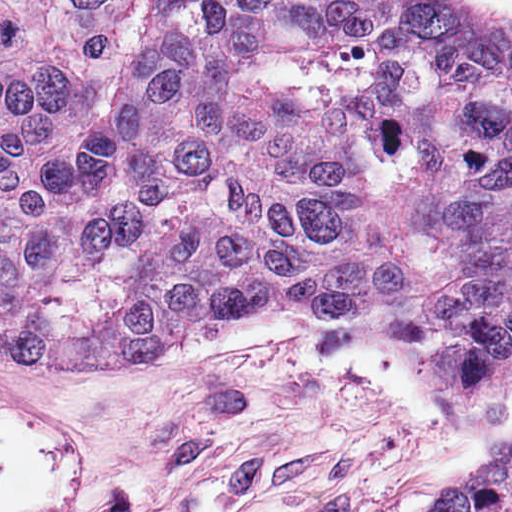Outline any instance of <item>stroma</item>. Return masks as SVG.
I'll return each mask as SVG.
<instances>
[{"label": "stroma", "instance_id": "stroma-1", "mask_svg": "<svg viewBox=\"0 0 512 512\" xmlns=\"http://www.w3.org/2000/svg\"><path fill=\"white\" fill-rule=\"evenodd\" d=\"M512 11V0H490ZM421 512L496 471L512 455V396L455 408L425 351L374 315L333 312Z\"/></svg>", "mask_w": 512, "mask_h": 512}]
</instances>
